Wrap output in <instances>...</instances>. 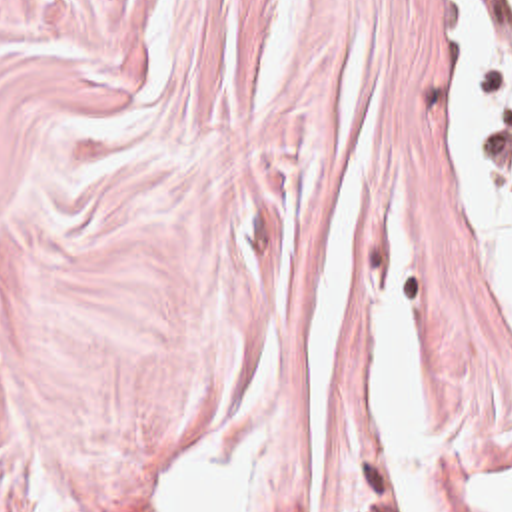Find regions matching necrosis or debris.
Instances as JSON below:
<instances>
[{"label":"necrosis or debris","mask_w":512,"mask_h":512,"mask_svg":"<svg viewBox=\"0 0 512 512\" xmlns=\"http://www.w3.org/2000/svg\"><path fill=\"white\" fill-rule=\"evenodd\" d=\"M500 32L504 44V98H506V134L512 156V0H500Z\"/></svg>","instance_id":"necrosis-or-debris-1"}]
</instances>
